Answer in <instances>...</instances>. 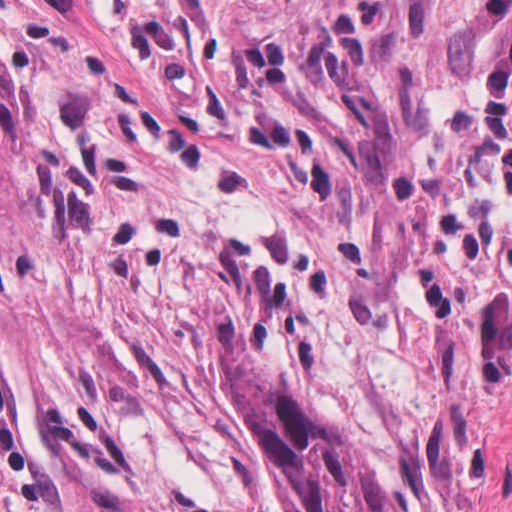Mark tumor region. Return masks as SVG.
I'll list each match as a JSON object with an SVG mask.
<instances>
[{
  "label": "tumor region",
  "mask_w": 512,
  "mask_h": 512,
  "mask_svg": "<svg viewBox=\"0 0 512 512\" xmlns=\"http://www.w3.org/2000/svg\"><path fill=\"white\" fill-rule=\"evenodd\" d=\"M340 36H304L244 56V74L271 111L320 129L350 155L370 191L390 189L401 117ZM22 218L20 94L0 60V229ZM243 405L300 512H392L379 473L358 445L300 395L260 376L246 339H223Z\"/></svg>",
  "instance_id": "obj_1"
}]
</instances>
